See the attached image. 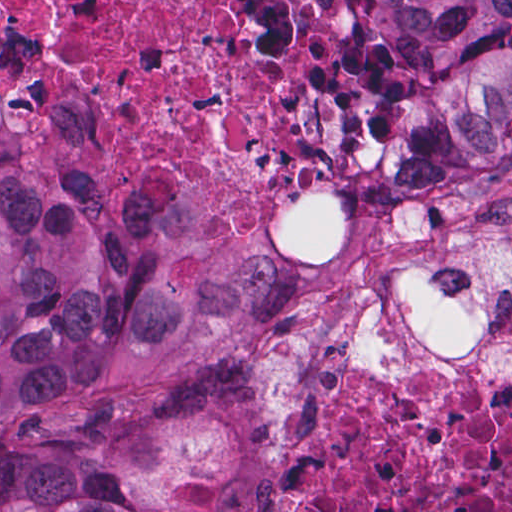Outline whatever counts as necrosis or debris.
<instances>
[{
  "label": "necrosis or debris",
  "instance_id": "obj_1",
  "mask_svg": "<svg viewBox=\"0 0 512 512\" xmlns=\"http://www.w3.org/2000/svg\"><path fill=\"white\" fill-rule=\"evenodd\" d=\"M0 43L114 181L241 245L329 240L377 129L348 0H0ZM271 512H512V378L418 410L324 361Z\"/></svg>",
  "mask_w": 512,
  "mask_h": 512
}]
</instances>
